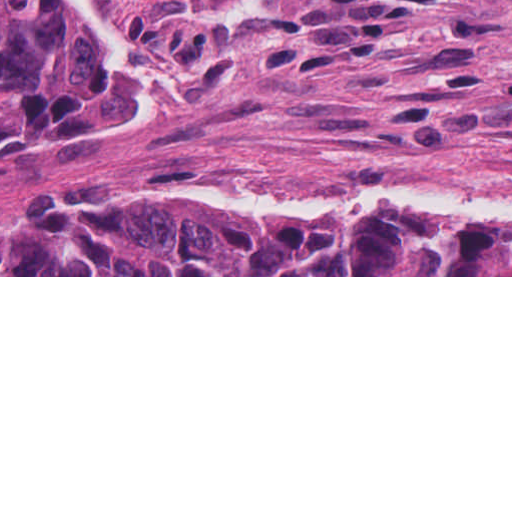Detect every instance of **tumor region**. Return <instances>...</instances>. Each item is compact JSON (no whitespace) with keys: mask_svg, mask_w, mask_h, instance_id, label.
Masks as SVG:
<instances>
[{"mask_svg":"<svg viewBox=\"0 0 512 512\" xmlns=\"http://www.w3.org/2000/svg\"><path fill=\"white\" fill-rule=\"evenodd\" d=\"M110 84L66 0H0V167L90 138ZM0 275H512V229L385 209L329 230L186 198L0 226Z\"/></svg>","mask_w":512,"mask_h":512,"instance_id":"e687c5a6","label":"tumor region"}]
</instances>
